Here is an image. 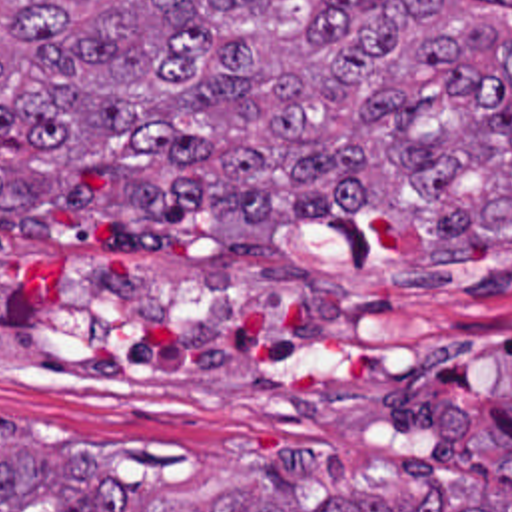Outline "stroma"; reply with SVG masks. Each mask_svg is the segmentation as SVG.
I'll list each match as a JSON object with an SVG mask.
<instances>
[{
    "mask_svg": "<svg viewBox=\"0 0 512 512\" xmlns=\"http://www.w3.org/2000/svg\"><path fill=\"white\" fill-rule=\"evenodd\" d=\"M512 42V0L462 4ZM0 234V425L131 497H201L275 453L296 499L428 501L398 463L512 507V250L422 262L388 216L231 250L207 206L161 248L53 204Z\"/></svg>",
    "mask_w": 512,
    "mask_h": 512,
    "instance_id": "1",
    "label": "stroma"
}]
</instances>
